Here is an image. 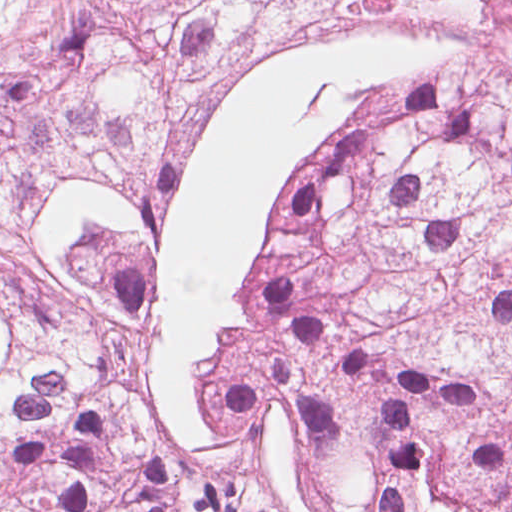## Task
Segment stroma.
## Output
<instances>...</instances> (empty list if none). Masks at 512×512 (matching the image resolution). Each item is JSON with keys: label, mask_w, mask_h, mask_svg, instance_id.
<instances>
[{"label": "stroma", "mask_w": 512, "mask_h": 512, "mask_svg": "<svg viewBox=\"0 0 512 512\" xmlns=\"http://www.w3.org/2000/svg\"><path fill=\"white\" fill-rule=\"evenodd\" d=\"M479 39L370 6L317 17L232 60L163 162L159 246L139 302V375L167 458L206 461L220 385L281 347V267L347 131Z\"/></svg>", "instance_id": "stroma-1"}]
</instances>
